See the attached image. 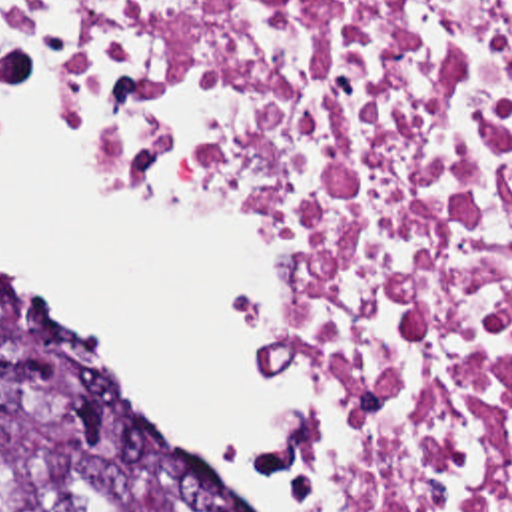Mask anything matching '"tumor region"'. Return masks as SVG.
I'll list each match as a JSON object with an SVG mask.
<instances>
[{
  "label": "tumor region",
  "mask_w": 512,
  "mask_h": 512,
  "mask_svg": "<svg viewBox=\"0 0 512 512\" xmlns=\"http://www.w3.org/2000/svg\"><path fill=\"white\" fill-rule=\"evenodd\" d=\"M0 512H229L1 278Z\"/></svg>",
  "instance_id": "1"
}]
</instances>
